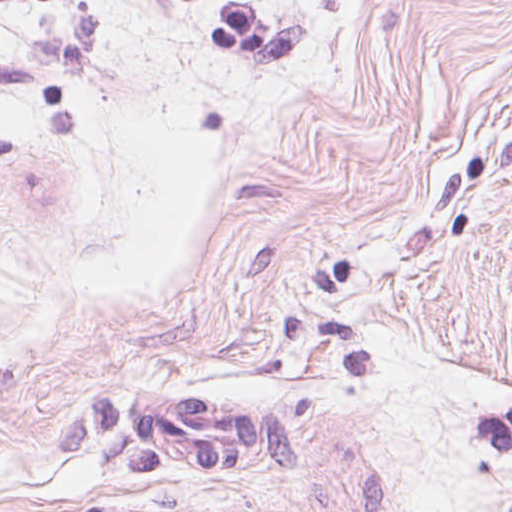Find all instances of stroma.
Returning <instances> with one entry per match:
<instances>
[{
  "label": "stroma",
  "mask_w": 512,
  "mask_h": 512,
  "mask_svg": "<svg viewBox=\"0 0 512 512\" xmlns=\"http://www.w3.org/2000/svg\"><path fill=\"white\" fill-rule=\"evenodd\" d=\"M181 99L188 267L74 288L2 512H512V0H169Z\"/></svg>",
  "instance_id": "1"
}]
</instances>
